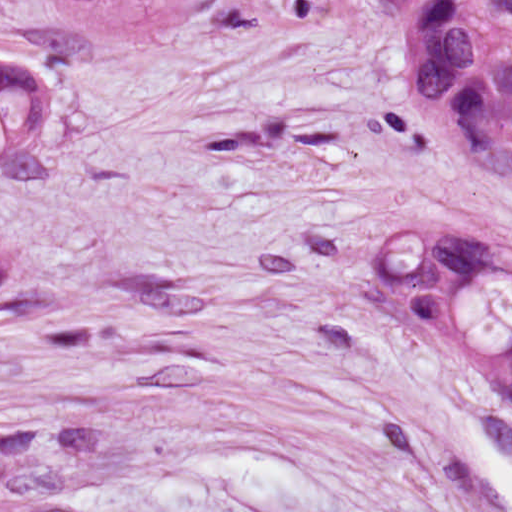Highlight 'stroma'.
Masks as SVG:
<instances>
[{"mask_svg":"<svg viewBox=\"0 0 512 512\" xmlns=\"http://www.w3.org/2000/svg\"><path fill=\"white\" fill-rule=\"evenodd\" d=\"M512 250V170L415 105L0 288V512H512V403L366 282Z\"/></svg>","mask_w":512,"mask_h":512,"instance_id":"obj_1","label":"stroma"}]
</instances>
